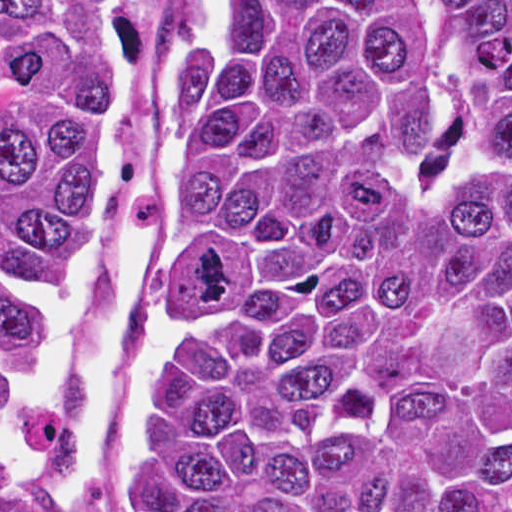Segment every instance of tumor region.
I'll use <instances>...</instances> for the list:
<instances>
[{
	"label": "tumor region",
	"mask_w": 512,
	"mask_h": 512,
	"mask_svg": "<svg viewBox=\"0 0 512 512\" xmlns=\"http://www.w3.org/2000/svg\"><path fill=\"white\" fill-rule=\"evenodd\" d=\"M185 1L124 512H512V0H211L173 69ZM122 4L0 0V481L66 435Z\"/></svg>",
	"instance_id": "obj_1"
}]
</instances>
